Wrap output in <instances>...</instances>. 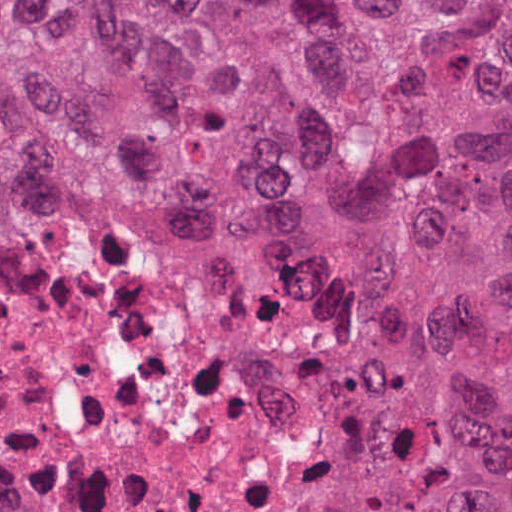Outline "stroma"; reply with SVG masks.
Returning a JSON list of instances; mask_svg holds the SVG:
<instances>
[{"mask_svg":"<svg viewBox=\"0 0 512 512\" xmlns=\"http://www.w3.org/2000/svg\"><path fill=\"white\" fill-rule=\"evenodd\" d=\"M0 1H512V0H0ZM146 229H184L179 227H151ZM53 246H27L0 252V266H15L30 255ZM336 512H342V463L336 488Z\"/></svg>","mask_w":512,"mask_h":512,"instance_id":"35a3bbf8","label":"stroma"}]
</instances>
